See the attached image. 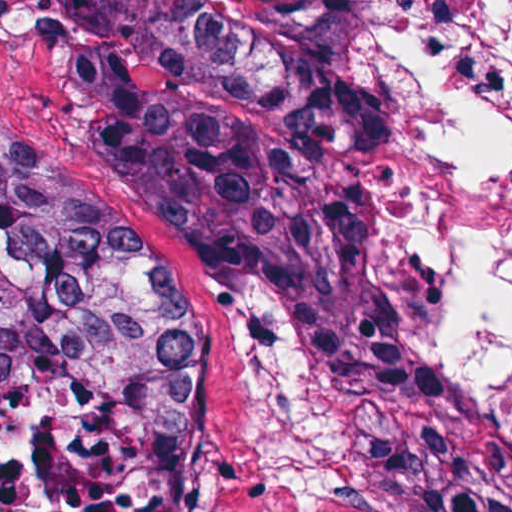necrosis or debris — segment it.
Instances as JSON below:
<instances>
[{"label": "necrosis or debris", "instance_id": "4bbe7bcc", "mask_svg": "<svg viewBox=\"0 0 512 512\" xmlns=\"http://www.w3.org/2000/svg\"><path fill=\"white\" fill-rule=\"evenodd\" d=\"M178 411L135 344L58 337L0 380V512H152Z\"/></svg>", "mask_w": 512, "mask_h": 512}]
</instances>
